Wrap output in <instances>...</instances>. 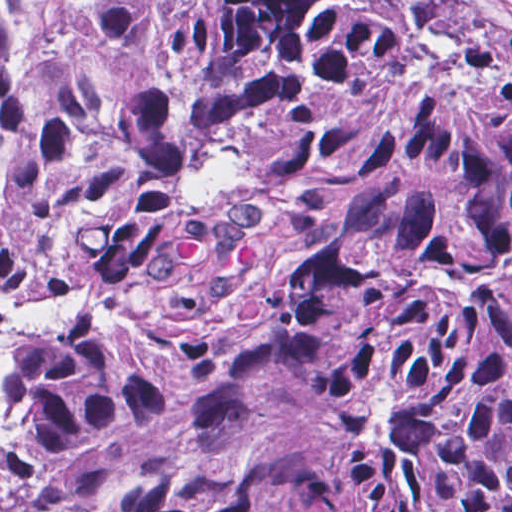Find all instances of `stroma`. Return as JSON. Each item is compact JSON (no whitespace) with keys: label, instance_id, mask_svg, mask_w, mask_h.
Listing matches in <instances>:
<instances>
[{"label":"stroma","instance_id":"stroma-1","mask_svg":"<svg viewBox=\"0 0 512 512\" xmlns=\"http://www.w3.org/2000/svg\"><path fill=\"white\" fill-rule=\"evenodd\" d=\"M500 1L503 2L505 5H507L510 9H512V0H500ZM334 440L337 443V445L339 446V448L342 450V452L345 454V456L348 458L349 461L362 463V464H378V463L370 462V461L366 460L365 458L361 457L360 455L356 454L355 452L351 451L350 449L346 448L335 438H334Z\"/></svg>","mask_w":512,"mask_h":512}]
</instances>
